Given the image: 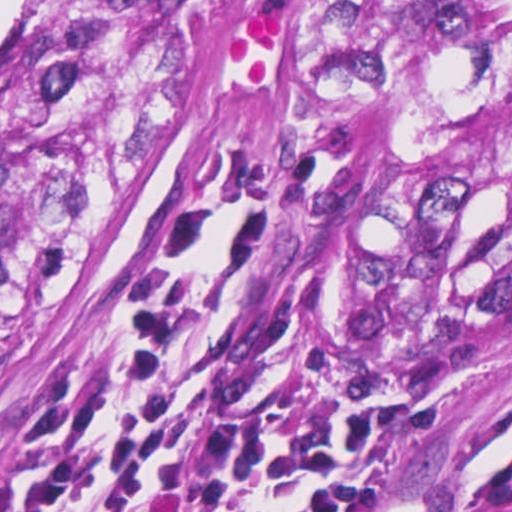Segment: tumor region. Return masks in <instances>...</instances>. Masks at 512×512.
I'll return each mask as SVG.
<instances>
[{
	"label": "tumor region",
	"mask_w": 512,
	"mask_h": 512,
	"mask_svg": "<svg viewBox=\"0 0 512 512\" xmlns=\"http://www.w3.org/2000/svg\"><path fill=\"white\" fill-rule=\"evenodd\" d=\"M249 121L321 152L422 341L510 324L512 0H37L0 45V342ZM459 512H512V442Z\"/></svg>",
	"instance_id": "e687c5a6"
}]
</instances>
